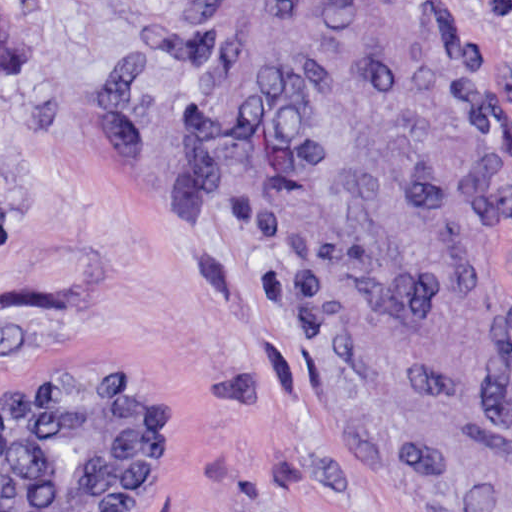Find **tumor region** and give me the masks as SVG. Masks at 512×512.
<instances>
[{
	"label": "tumor region",
	"mask_w": 512,
	"mask_h": 512,
	"mask_svg": "<svg viewBox=\"0 0 512 512\" xmlns=\"http://www.w3.org/2000/svg\"><path fill=\"white\" fill-rule=\"evenodd\" d=\"M31 24H0V67ZM175 403L33 376L0 392V512H136Z\"/></svg>",
	"instance_id": "1"
}]
</instances>
